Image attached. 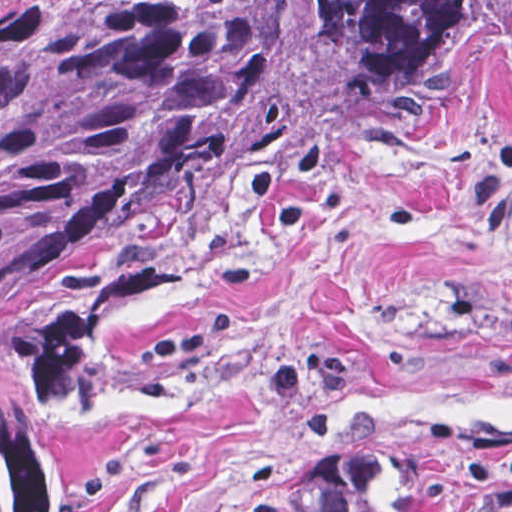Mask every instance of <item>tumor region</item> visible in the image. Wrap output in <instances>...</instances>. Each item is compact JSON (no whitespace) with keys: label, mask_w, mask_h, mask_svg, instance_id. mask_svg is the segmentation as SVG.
Wrapping results in <instances>:
<instances>
[{"label":"tumor region","mask_w":512,"mask_h":512,"mask_svg":"<svg viewBox=\"0 0 512 512\" xmlns=\"http://www.w3.org/2000/svg\"><path fill=\"white\" fill-rule=\"evenodd\" d=\"M512 50V0H34L0 16V512H70L92 391L359 131ZM331 512H512V440H418Z\"/></svg>","instance_id":"1"}]
</instances>
